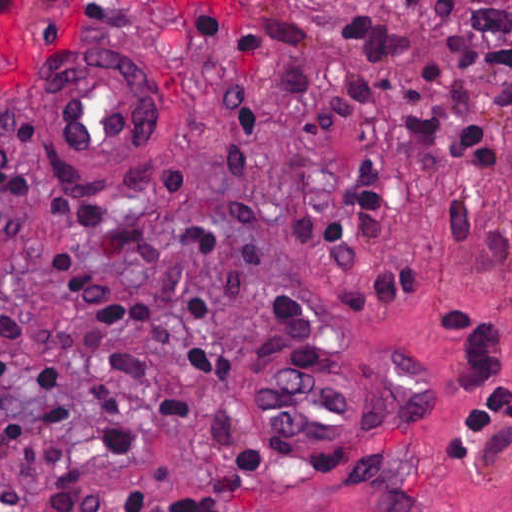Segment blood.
<instances>
[{"label": "blood", "mask_w": 512, "mask_h": 512, "mask_svg": "<svg viewBox=\"0 0 512 512\" xmlns=\"http://www.w3.org/2000/svg\"><path fill=\"white\" fill-rule=\"evenodd\" d=\"M46 1L48 0H0V21L2 22L19 12L33 10ZM179 1L195 13H207L222 23L225 22H223L214 13L235 12L243 10L244 7V0H195L210 10L203 11L186 0Z\"/></svg>", "instance_id": "obj_1"}]
</instances>
